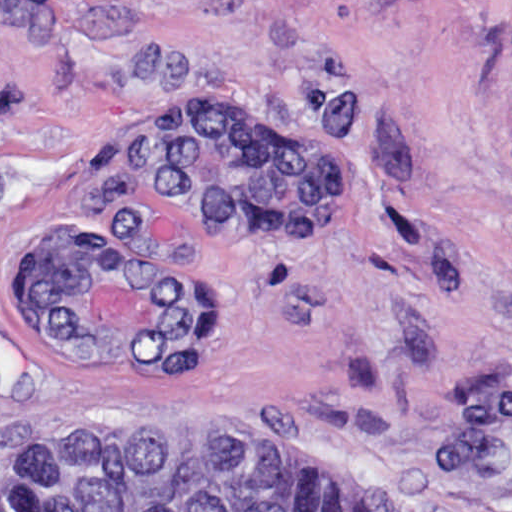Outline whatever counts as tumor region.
Segmentation results:
<instances>
[{
	"instance_id": "e687c5a6",
	"label": "tumor region",
	"mask_w": 512,
	"mask_h": 512,
	"mask_svg": "<svg viewBox=\"0 0 512 512\" xmlns=\"http://www.w3.org/2000/svg\"><path fill=\"white\" fill-rule=\"evenodd\" d=\"M133 173L208 236L272 251L330 230L325 166L279 110L204 91L134 135ZM19 289L65 362L191 369L210 354L216 291L150 240L48 221L19 262ZM0 512H373L312 465L242 439L61 431L29 441L0 478Z\"/></svg>"
}]
</instances>
